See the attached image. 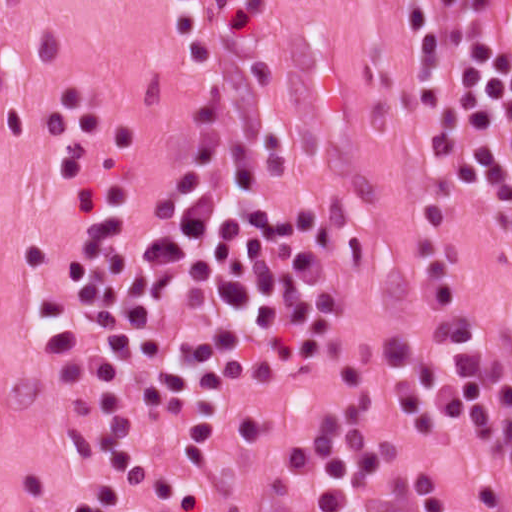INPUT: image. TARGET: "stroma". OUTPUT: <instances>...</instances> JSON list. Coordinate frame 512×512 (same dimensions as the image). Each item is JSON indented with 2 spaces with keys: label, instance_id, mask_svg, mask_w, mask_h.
Wrapping results in <instances>:
<instances>
[{
  "label": "stroma",
  "instance_id": "stroma-1",
  "mask_svg": "<svg viewBox=\"0 0 512 512\" xmlns=\"http://www.w3.org/2000/svg\"><path fill=\"white\" fill-rule=\"evenodd\" d=\"M177 1L0 0V512H63L99 479L69 444L75 424L117 415L92 346L89 257L188 117ZM240 6L273 179L313 186L336 217L340 287L242 421L194 438L141 427L142 451L179 490L144 492L136 512H313L280 452L358 401L374 407L380 473L433 482L458 512H494L496 464L420 434L392 348L399 302L441 234L512 365V214L449 198L404 0Z\"/></svg>",
  "mask_w": 512,
  "mask_h": 512
}]
</instances>
